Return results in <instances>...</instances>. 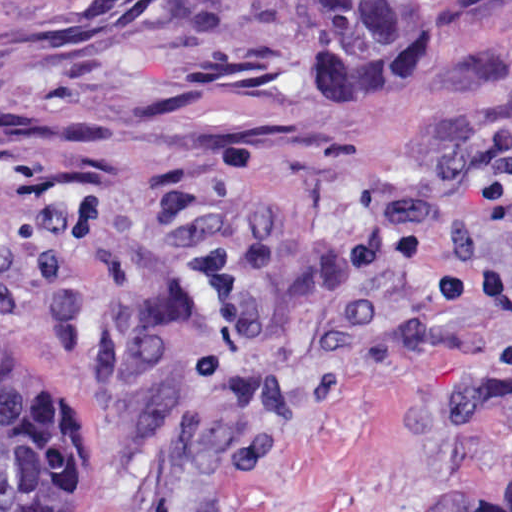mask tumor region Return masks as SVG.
<instances>
[{"label":"tumor region","mask_w":512,"mask_h":512,"mask_svg":"<svg viewBox=\"0 0 512 512\" xmlns=\"http://www.w3.org/2000/svg\"><path fill=\"white\" fill-rule=\"evenodd\" d=\"M350 31L364 74H391L441 35V0H311ZM77 385L52 357L0 332V512H66L83 474ZM426 512H512V469Z\"/></svg>","instance_id":"1"}]
</instances>
